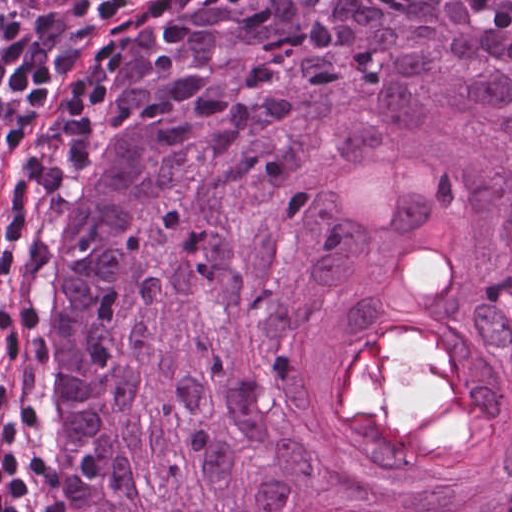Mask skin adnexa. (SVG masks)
I'll return each instance as SVG.
<instances>
[{"label": "skin adnexa", "mask_w": 512, "mask_h": 512, "mask_svg": "<svg viewBox=\"0 0 512 512\" xmlns=\"http://www.w3.org/2000/svg\"><path fill=\"white\" fill-rule=\"evenodd\" d=\"M111 143L43 512H512V0H202Z\"/></svg>", "instance_id": "obj_1"}]
</instances>
